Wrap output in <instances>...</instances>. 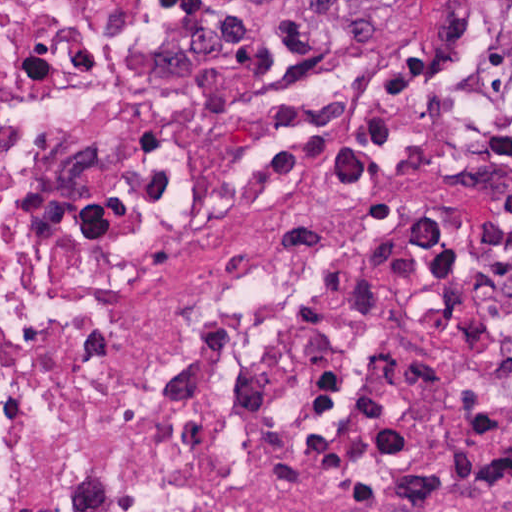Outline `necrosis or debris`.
Masks as SVG:
<instances>
[{
    "mask_svg": "<svg viewBox=\"0 0 512 512\" xmlns=\"http://www.w3.org/2000/svg\"><path fill=\"white\" fill-rule=\"evenodd\" d=\"M351 93L0 0V512H512L336 276Z\"/></svg>",
    "mask_w": 512,
    "mask_h": 512,
    "instance_id": "obj_1",
    "label": "necrosis or debris"
}]
</instances>
